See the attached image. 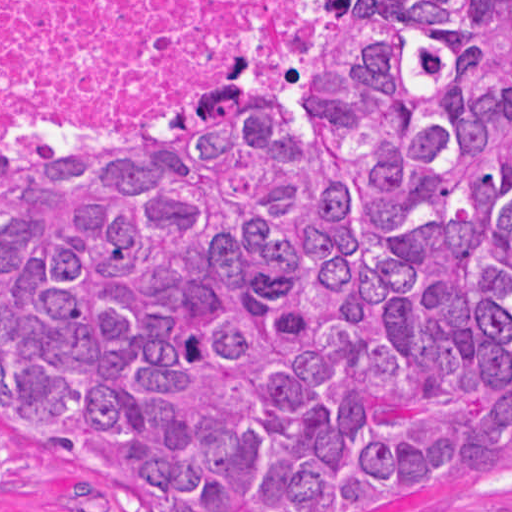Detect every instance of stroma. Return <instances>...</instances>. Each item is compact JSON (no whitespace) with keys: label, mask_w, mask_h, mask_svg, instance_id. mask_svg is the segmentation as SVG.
<instances>
[{"label":"stroma","mask_w":512,"mask_h":512,"mask_svg":"<svg viewBox=\"0 0 512 512\" xmlns=\"http://www.w3.org/2000/svg\"><path fill=\"white\" fill-rule=\"evenodd\" d=\"M0 512H162L153 491L0 424ZM419 512H512V437L466 462Z\"/></svg>","instance_id":"35a3bbf8"}]
</instances>
